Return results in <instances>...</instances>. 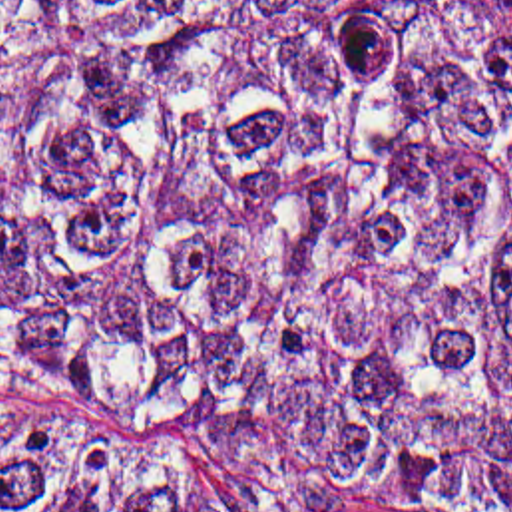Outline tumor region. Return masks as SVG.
<instances>
[{
    "label": "tumor region",
    "mask_w": 512,
    "mask_h": 512,
    "mask_svg": "<svg viewBox=\"0 0 512 512\" xmlns=\"http://www.w3.org/2000/svg\"><path fill=\"white\" fill-rule=\"evenodd\" d=\"M512 512V0H0V512Z\"/></svg>",
    "instance_id": "tumor-region-1"
}]
</instances>
